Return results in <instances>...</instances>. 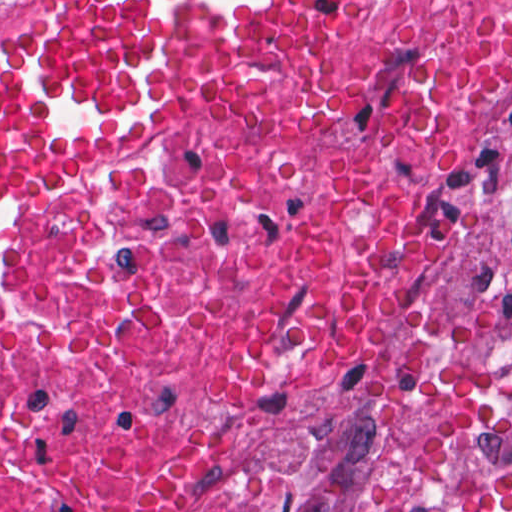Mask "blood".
<instances>
[{"label": "blood", "mask_w": 512, "mask_h": 512, "mask_svg": "<svg viewBox=\"0 0 512 512\" xmlns=\"http://www.w3.org/2000/svg\"><path fill=\"white\" fill-rule=\"evenodd\" d=\"M357 2L21 0L0 58V188L35 164L124 160L192 110L283 83Z\"/></svg>", "instance_id": "1a1defca"}]
</instances>
